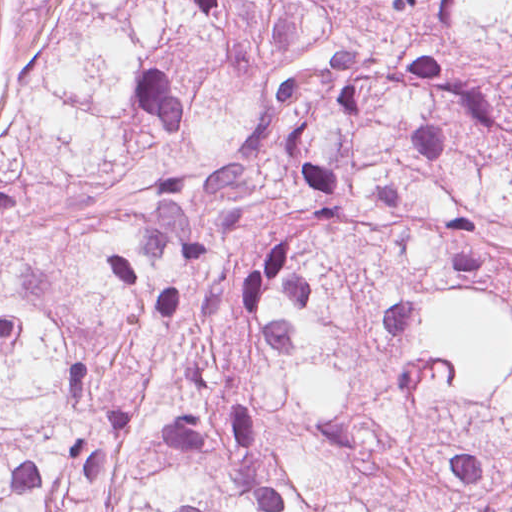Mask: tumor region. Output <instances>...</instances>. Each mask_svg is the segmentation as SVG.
Here are the masks:
<instances>
[{
    "mask_svg": "<svg viewBox=\"0 0 512 512\" xmlns=\"http://www.w3.org/2000/svg\"><path fill=\"white\" fill-rule=\"evenodd\" d=\"M59 1L0 92V512H512V0H406L385 73Z\"/></svg>",
    "mask_w": 512,
    "mask_h": 512,
    "instance_id": "1",
    "label": "tumor region"
}]
</instances>
